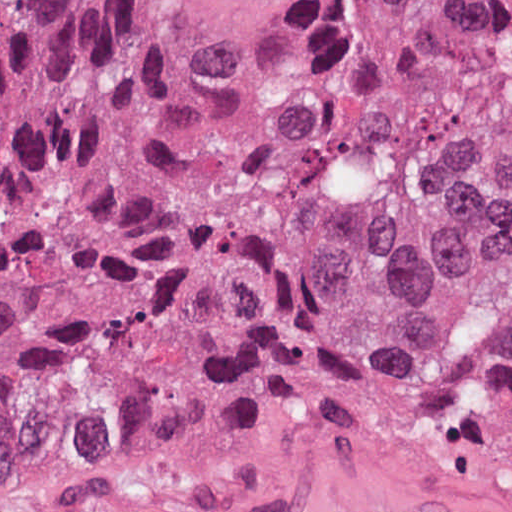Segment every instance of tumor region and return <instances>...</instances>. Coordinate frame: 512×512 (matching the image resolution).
I'll return each mask as SVG.
<instances>
[{
  "instance_id": "obj_1",
  "label": "tumor region",
  "mask_w": 512,
  "mask_h": 512,
  "mask_svg": "<svg viewBox=\"0 0 512 512\" xmlns=\"http://www.w3.org/2000/svg\"><path fill=\"white\" fill-rule=\"evenodd\" d=\"M308 404L512 493V0H0V483Z\"/></svg>"
}]
</instances>
